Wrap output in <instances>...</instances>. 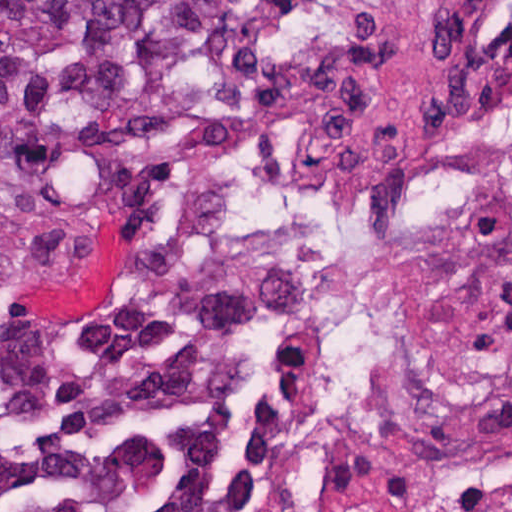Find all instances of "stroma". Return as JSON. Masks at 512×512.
Masks as SVG:
<instances>
[{
    "instance_id": "1",
    "label": "stroma",
    "mask_w": 512,
    "mask_h": 512,
    "mask_svg": "<svg viewBox=\"0 0 512 512\" xmlns=\"http://www.w3.org/2000/svg\"><path fill=\"white\" fill-rule=\"evenodd\" d=\"M246 1L257 60L161 172L46 217L0 219V230L70 226L99 242L79 269L12 302L1 335L26 319L61 326L93 315L145 223L189 226L265 347L242 423L246 454L274 479L277 512H298L295 362L252 271L242 185L260 162L371 153L400 138L427 111L488 0ZM12 495L15 512H27L13 434Z\"/></svg>"
}]
</instances>
